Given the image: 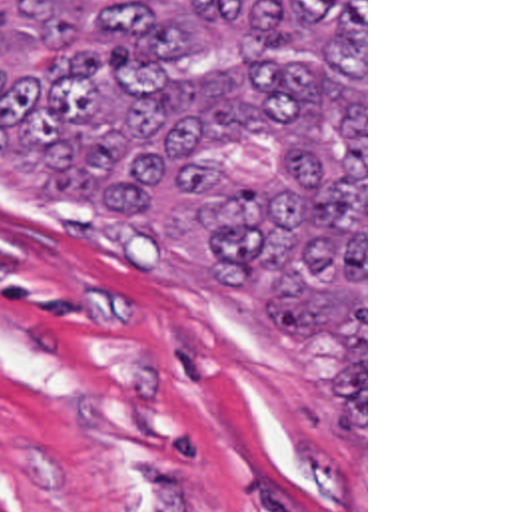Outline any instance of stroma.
<instances>
[{
	"instance_id": "35a3bbf8",
	"label": "stroma",
	"mask_w": 512,
	"mask_h": 512,
	"mask_svg": "<svg viewBox=\"0 0 512 512\" xmlns=\"http://www.w3.org/2000/svg\"><path fill=\"white\" fill-rule=\"evenodd\" d=\"M170 476L198 512H368V0L364 422L344 343L264 341L196 237L0 169V512H162Z\"/></svg>"
}]
</instances>
